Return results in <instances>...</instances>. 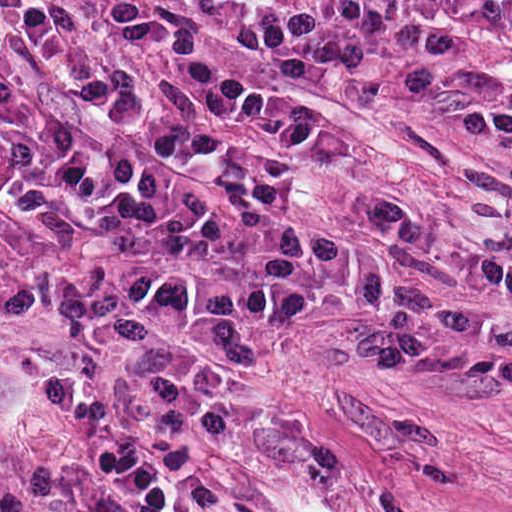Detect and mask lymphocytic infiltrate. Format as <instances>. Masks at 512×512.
<instances>
[{
    "instance_id": "1",
    "label": "lymphocytic infiltrate",
    "mask_w": 512,
    "mask_h": 512,
    "mask_svg": "<svg viewBox=\"0 0 512 512\" xmlns=\"http://www.w3.org/2000/svg\"><path fill=\"white\" fill-rule=\"evenodd\" d=\"M0 0V512H185L253 459L241 309L321 302L357 178L325 102L441 137L512 0Z\"/></svg>"
}]
</instances>
